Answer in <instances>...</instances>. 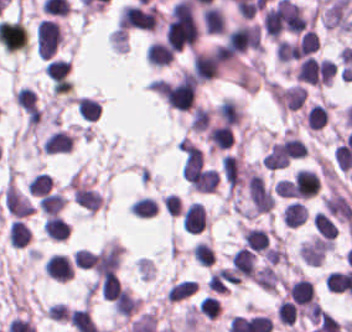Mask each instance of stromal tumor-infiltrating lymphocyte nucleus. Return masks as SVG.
<instances>
[{
  "instance_id": "obj_1",
  "label": "stromal tumor-infiltrating lymphocyte nucleus",
  "mask_w": 352,
  "mask_h": 332,
  "mask_svg": "<svg viewBox=\"0 0 352 332\" xmlns=\"http://www.w3.org/2000/svg\"><path fill=\"white\" fill-rule=\"evenodd\" d=\"M62 39V31L53 20L41 19L36 24L35 46L40 59H50Z\"/></svg>"
},
{
  "instance_id": "obj_2",
  "label": "stromal tumor-infiltrating lymphocyte nucleus",
  "mask_w": 352,
  "mask_h": 332,
  "mask_svg": "<svg viewBox=\"0 0 352 332\" xmlns=\"http://www.w3.org/2000/svg\"><path fill=\"white\" fill-rule=\"evenodd\" d=\"M42 269L53 279L66 281L72 277L74 267L68 255L59 252H52L42 260Z\"/></svg>"
},
{
  "instance_id": "obj_3",
  "label": "stromal tumor-infiltrating lymphocyte nucleus",
  "mask_w": 352,
  "mask_h": 332,
  "mask_svg": "<svg viewBox=\"0 0 352 332\" xmlns=\"http://www.w3.org/2000/svg\"><path fill=\"white\" fill-rule=\"evenodd\" d=\"M209 219L200 202H193L186 207L181 217V228L187 233H198L207 228Z\"/></svg>"
},
{
  "instance_id": "obj_4",
  "label": "stromal tumor-infiltrating lymphocyte nucleus",
  "mask_w": 352,
  "mask_h": 332,
  "mask_svg": "<svg viewBox=\"0 0 352 332\" xmlns=\"http://www.w3.org/2000/svg\"><path fill=\"white\" fill-rule=\"evenodd\" d=\"M72 143L73 136L68 130L56 128L45 136L40 147L45 154H53L69 151Z\"/></svg>"
},
{
  "instance_id": "obj_5",
  "label": "stromal tumor-infiltrating lymphocyte nucleus",
  "mask_w": 352,
  "mask_h": 332,
  "mask_svg": "<svg viewBox=\"0 0 352 332\" xmlns=\"http://www.w3.org/2000/svg\"><path fill=\"white\" fill-rule=\"evenodd\" d=\"M174 58V51L161 40L154 39L145 48L146 63L154 66H167Z\"/></svg>"
},
{
  "instance_id": "obj_6",
  "label": "stromal tumor-infiltrating lymphocyte nucleus",
  "mask_w": 352,
  "mask_h": 332,
  "mask_svg": "<svg viewBox=\"0 0 352 332\" xmlns=\"http://www.w3.org/2000/svg\"><path fill=\"white\" fill-rule=\"evenodd\" d=\"M307 210L301 201H288L284 203L280 219L282 223L290 226H297L305 221Z\"/></svg>"
},
{
  "instance_id": "obj_7",
  "label": "stromal tumor-infiltrating lymphocyte nucleus",
  "mask_w": 352,
  "mask_h": 332,
  "mask_svg": "<svg viewBox=\"0 0 352 332\" xmlns=\"http://www.w3.org/2000/svg\"><path fill=\"white\" fill-rule=\"evenodd\" d=\"M66 203V195L60 191L46 192L37 201L40 212L47 215L59 213Z\"/></svg>"
},
{
  "instance_id": "obj_8",
  "label": "stromal tumor-infiltrating lymphocyte nucleus",
  "mask_w": 352,
  "mask_h": 332,
  "mask_svg": "<svg viewBox=\"0 0 352 332\" xmlns=\"http://www.w3.org/2000/svg\"><path fill=\"white\" fill-rule=\"evenodd\" d=\"M29 238L30 232L26 224L16 218L6 228V239L13 248H22Z\"/></svg>"
},
{
  "instance_id": "obj_9",
  "label": "stromal tumor-infiltrating lymphocyte nucleus",
  "mask_w": 352,
  "mask_h": 332,
  "mask_svg": "<svg viewBox=\"0 0 352 332\" xmlns=\"http://www.w3.org/2000/svg\"><path fill=\"white\" fill-rule=\"evenodd\" d=\"M45 235L52 239H66L70 227L61 216H47L42 224Z\"/></svg>"
},
{
  "instance_id": "obj_10",
  "label": "stromal tumor-infiltrating lymphocyte nucleus",
  "mask_w": 352,
  "mask_h": 332,
  "mask_svg": "<svg viewBox=\"0 0 352 332\" xmlns=\"http://www.w3.org/2000/svg\"><path fill=\"white\" fill-rule=\"evenodd\" d=\"M75 104L80 115L88 121H95L102 114L101 102L95 98L77 96Z\"/></svg>"
},
{
  "instance_id": "obj_11",
  "label": "stromal tumor-infiltrating lymphocyte nucleus",
  "mask_w": 352,
  "mask_h": 332,
  "mask_svg": "<svg viewBox=\"0 0 352 332\" xmlns=\"http://www.w3.org/2000/svg\"><path fill=\"white\" fill-rule=\"evenodd\" d=\"M159 205L152 196H139L134 198L129 213L139 217H151L156 214Z\"/></svg>"
},
{
  "instance_id": "obj_12",
  "label": "stromal tumor-infiltrating lymphocyte nucleus",
  "mask_w": 352,
  "mask_h": 332,
  "mask_svg": "<svg viewBox=\"0 0 352 332\" xmlns=\"http://www.w3.org/2000/svg\"><path fill=\"white\" fill-rule=\"evenodd\" d=\"M53 183L51 174L46 171H39L26 185L27 190L34 196H42L50 192Z\"/></svg>"
},
{
  "instance_id": "obj_13",
  "label": "stromal tumor-infiltrating lymphocyte nucleus",
  "mask_w": 352,
  "mask_h": 332,
  "mask_svg": "<svg viewBox=\"0 0 352 332\" xmlns=\"http://www.w3.org/2000/svg\"><path fill=\"white\" fill-rule=\"evenodd\" d=\"M197 285L193 279L182 278L175 282L165 293L170 301H178L196 291Z\"/></svg>"
},
{
  "instance_id": "obj_14",
  "label": "stromal tumor-infiltrating lymphocyte nucleus",
  "mask_w": 352,
  "mask_h": 332,
  "mask_svg": "<svg viewBox=\"0 0 352 332\" xmlns=\"http://www.w3.org/2000/svg\"><path fill=\"white\" fill-rule=\"evenodd\" d=\"M68 72H69V62L67 58H57V57L49 61L44 71L45 75L56 83L64 80Z\"/></svg>"
},
{
  "instance_id": "obj_15",
  "label": "stromal tumor-infiltrating lymphocyte nucleus",
  "mask_w": 352,
  "mask_h": 332,
  "mask_svg": "<svg viewBox=\"0 0 352 332\" xmlns=\"http://www.w3.org/2000/svg\"><path fill=\"white\" fill-rule=\"evenodd\" d=\"M192 255L204 265H211L214 261V251L208 242L196 241L192 246Z\"/></svg>"
},
{
  "instance_id": "obj_16",
  "label": "stromal tumor-infiltrating lymphocyte nucleus",
  "mask_w": 352,
  "mask_h": 332,
  "mask_svg": "<svg viewBox=\"0 0 352 332\" xmlns=\"http://www.w3.org/2000/svg\"><path fill=\"white\" fill-rule=\"evenodd\" d=\"M197 311L213 320L221 314L218 298L208 294L202 296L198 303Z\"/></svg>"
},
{
  "instance_id": "obj_17",
  "label": "stromal tumor-infiltrating lymphocyte nucleus",
  "mask_w": 352,
  "mask_h": 332,
  "mask_svg": "<svg viewBox=\"0 0 352 332\" xmlns=\"http://www.w3.org/2000/svg\"><path fill=\"white\" fill-rule=\"evenodd\" d=\"M72 259L82 269H89L94 264L92 253L89 249L79 248L72 253Z\"/></svg>"
}]
</instances>
